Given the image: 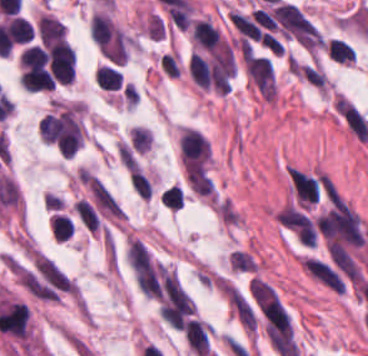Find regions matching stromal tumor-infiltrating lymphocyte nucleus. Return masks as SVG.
Returning <instances> with one entry per match:
<instances>
[{
    "label": "stromal tumor-infiltrating lymphocyte nucleus",
    "mask_w": 368,
    "mask_h": 356,
    "mask_svg": "<svg viewBox=\"0 0 368 356\" xmlns=\"http://www.w3.org/2000/svg\"><path fill=\"white\" fill-rule=\"evenodd\" d=\"M228 17L234 29L244 39L258 41L260 33L255 20L251 16L230 9L228 11Z\"/></svg>",
    "instance_id": "2"
},
{
    "label": "stromal tumor-infiltrating lymphocyte nucleus",
    "mask_w": 368,
    "mask_h": 356,
    "mask_svg": "<svg viewBox=\"0 0 368 356\" xmlns=\"http://www.w3.org/2000/svg\"><path fill=\"white\" fill-rule=\"evenodd\" d=\"M129 140L135 151L144 153L150 144L151 137L146 128L134 125L129 132Z\"/></svg>",
    "instance_id": "8"
},
{
    "label": "stromal tumor-infiltrating lymphocyte nucleus",
    "mask_w": 368,
    "mask_h": 356,
    "mask_svg": "<svg viewBox=\"0 0 368 356\" xmlns=\"http://www.w3.org/2000/svg\"><path fill=\"white\" fill-rule=\"evenodd\" d=\"M74 212L79 222L94 233L97 227V220L91 204L84 200H76Z\"/></svg>",
    "instance_id": "7"
},
{
    "label": "stromal tumor-infiltrating lymphocyte nucleus",
    "mask_w": 368,
    "mask_h": 356,
    "mask_svg": "<svg viewBox=\"0 0 368 356\" xmlns=\"http://www.w3.org/2000/svg\"><path fill=\"white\" fill-rule=\"evenodd\" d=\"M129 184L141 198L149 199L151 194L150 184L140 169L135 167L132 170Z\"/></svg>",
    "instance_id": "9"
},
{
    "label": "stromal tumor-infiltrating lymphocyte nucleus",
    "mask_w": 368,
    "mask_h": 356,
    "mask_svg": "<svg viewBox=\"0 0 368 356\" xmlns=\"http://www.w3.org/2000/svg\"><path fill=\"white\" fill-rule=\"evenodd\" d=\"M74 226L72 222L61 213H54L50 221L52 238L66 240L69 238Z\"/></svg>",
    "instance_id": "6"
},
{
    "label": "stromal tumor-infiltrating lymphocyte nucleus",
    "mask_w": 368,
    "mask_h": 356,
    "mask_svg": "<svg viewBox=\"0 0 368 356\" xmlns=\"http://www.w3.org/2000/svg\"><path fill=\"white\" fill-rule=\"evenodd\" d=\"M326 51L328 56L336 61L348 64L355 61L354 50L338 38H331L326 43Z\"/></svg>",
    "instance_id": "5"
},
{
    "label": "stromal tumor-infiltrating lymphocyte nucleus",
    "mask_w": 368,
    "mask_h": 356,
    "mask_svg": "<svg viewBox=\"0 0 368 356\" xmlns=\"http://www.w3.org/2000/svg\"><path fill=\"white\" fill-rule=\"evenodd\" d=\"M62 129V119L53 114H45L41 117L38 133L42 141L54 142L56 141L60 131Z\"/></svg>",
    "instance_id": "3"
},
{
    "label": "stromal tumor-infiltrating lymphocyte nucleus",
    "mask_w": 368,
    "mask_h": 356,
    "mask_svg": "<svg viewBox=\"0 0 368 356\" xmlns=\"http://www.w3.org/2000/svg\"><path fill=\"white\" fill-rule=\"evenodd\" d=\"M167 190L171 198L173 199L177 209L179 210L181 202L184 198V190L182 188H167Z\"/></svg>",
    "instance_id": "10"
},
{
    "label": "stromal tumor-infiltrating lymphocyte nucleus",
    "mask_w": 368,
    "mask_h": 356,
    "mask_svg": "<svg viewBox=\"0 0 368 356\" xmlns=\"http://www.w3.org/2000/svg\"><path fill=\"white\" fill-rule=\"evenodd\" d=\"M210 328L198 318H190L183 325V334L196 356H205Z\"/></svg>",
    "instance_id": "1"
},
{
    "label": "stromal tumor-infiltrating lymphocyte nucleus",
    "mask_w": 368,
    "mask_h": 356,
    "mask_svg": "<svg viewBox=\"0 0 368 356\" xmlns=\"http://www.w3.org/2000/svg\"><path fill=\"white\" fill-rule=\"evenodd\" d=\"M120 73L110 65H103L94 73L96 85L103 90H117Z\"/></svg>",
    "instance_id": "4"
}]
</instances>
